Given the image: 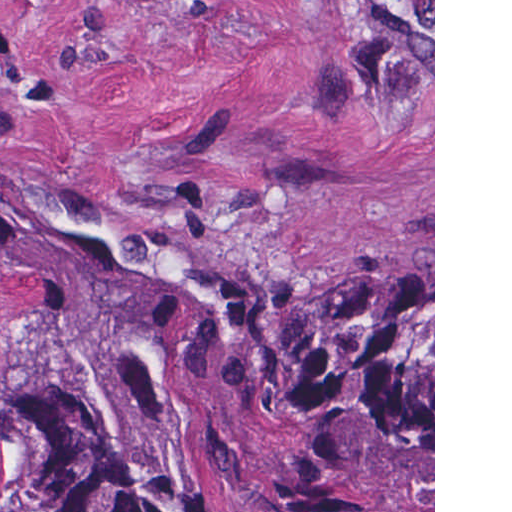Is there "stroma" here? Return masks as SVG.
Returning a JSON list of instances; mask_svg holds the SVG:
<instances>
[{
	"instance_id": "stroma-1",
	"label": "stroma",
	"mask_w": 512,
	"mask_h": 512,
	"mask_svg": "<svg viewBox=\"0 0 512 512\" xmlns=\"http://www.w3.org/2000/svg\"><path fill=\"white\" fill-rule=\"evenodd\" d=\"M287 293L433 268L435 0H0V190ZM31 327L0 294V364Z\"/></svg>"
}]
</instances>
